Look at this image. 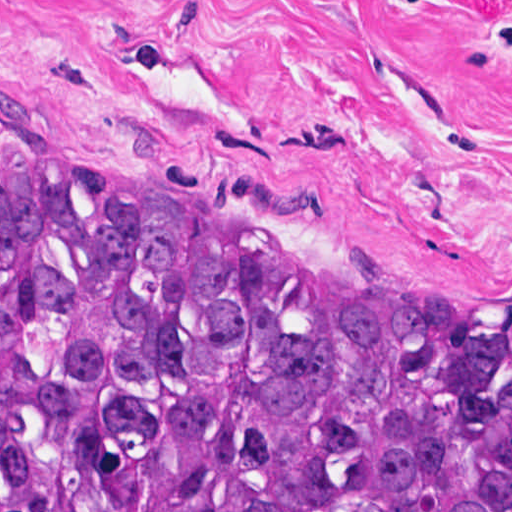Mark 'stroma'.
<instances>
[{
    "label": "stroma",
    "mask_w": 512,
    "mask_h": 512,
    "mask_svg": "<svg viewBox=\"0 0 512 512\" xmlns=\"http://www.w3.org/2000/svg\"><path fill=\"white\" fill-rule=\"evenodd\" d=\"M0 174L512 340V0H0Z\"/></svg>",
    "instance_id": "35a3bbf8"
}]
</instances>
